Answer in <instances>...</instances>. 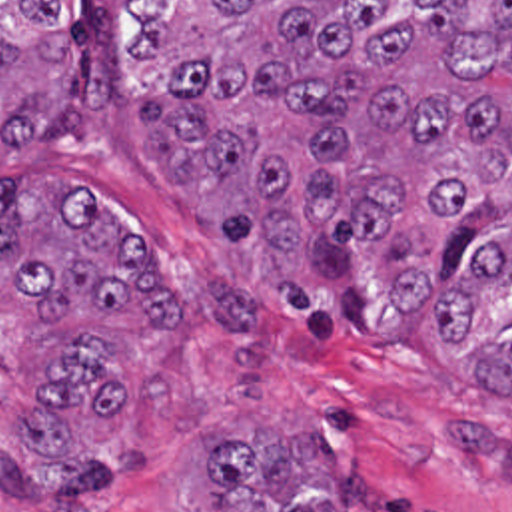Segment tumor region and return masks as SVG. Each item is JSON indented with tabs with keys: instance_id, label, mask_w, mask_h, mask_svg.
I'll use <instances>...</instances> for the list:
<instances>
[{
	"instance_id": "tumor-region-1",
	"label": "tumor region",
	"mask_w": 512,
	"mask_h": 512,
	"mask_svg": "<svg viewBox=\"0 0 512 512\" xmlns=\"http://www.w3.org/2000/svg\"><path fill=\"white\" fill-rule=\"evenodd\" d=\"M125 99L141 151L201 223L259 257L305 329H383L435 279L441 349L512 281V0H0V157L87 143ZM91 191L23 171L0 185V273L39 311L123 333H193L195 303ZM105 335L35 366L21 450L73 452L75 412L115 424L123 374ZM512 392V325L476 376ZM305 434L201 448L211 512H345ZM137 446L1 462L0 488L63 512L139 478Z\"/></svg>"
}]
</instances>
